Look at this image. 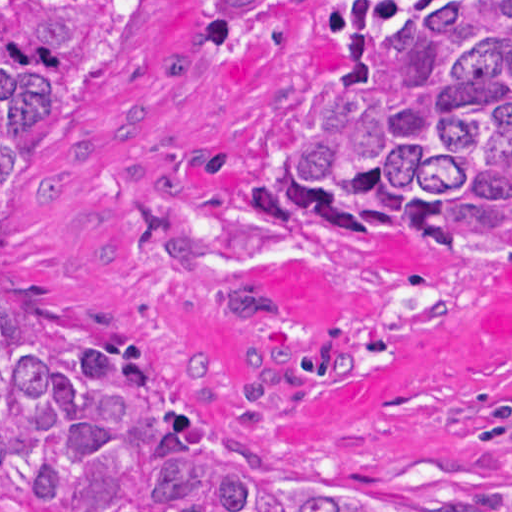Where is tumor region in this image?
<instances>
[{
  "label": "tumor region",
  "mask_w": 512,
  "mask_h": 512,
  "mask_svg": "<svg viewBox=\"0 0 512 512\" xmlns=\"http://www.w3.org/2000/svg\"><path fill=\"white\" fill-rule=\"evenodd\" d=\"M128 0H1V228ZM284 0H209L227 55ZM359 233H426L512 265V0L357 14L333 103L285 183ZM1 278V512H512V488L402 493L295 467L192 394L170 351L86 328Z\"/></svg>",
  "instance_id": "tumor-region-1"
}]
</instances>
